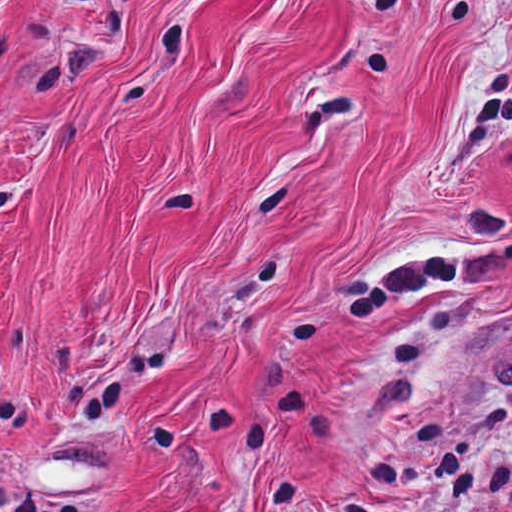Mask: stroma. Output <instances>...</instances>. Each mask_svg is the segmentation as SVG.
I'll list each match as a JSON object with an SVG mask.
<instances>
[{
	"instance_id": "obj_1",
	"label": "stroma",
	"mask_w": 512,
	"mask_h": 512,
	"mask_svg": "<svg viewBox=\"0 0 512 512\" xmlns=\"http://www.w3.org/2000/svg\"><path fill=\"white\" fill-rule=\"evenodd\" d=\"M0 512H512V0H0Z\"/></svg>"
}]
</instances>
